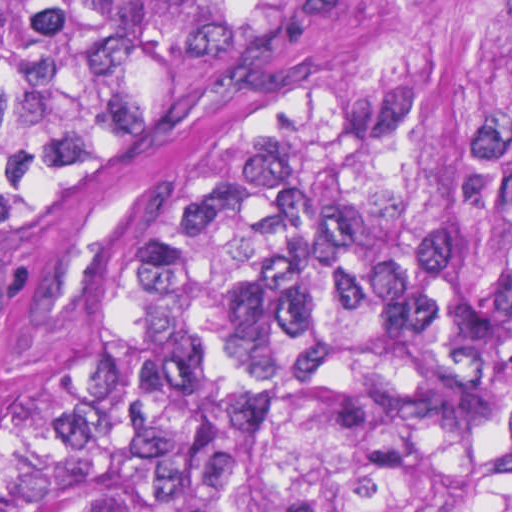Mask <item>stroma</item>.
I'll return each mask as SVG.
<instances>
[{
	"label": "stroma",
	"instance_id": "35a3bbf8",
	"mask_svg": "<svg viewBox=\"0 0 512 512\" xmlns=\"http://www.w3.org/2000/svg\"><path fill=\"white\" fill-rule=\"evenodd\" d=\"M27 311L20 289L0 314V423L8 386L29 359L23 343Z\"/></svg>",
	"mask_w": 512,
	"mask_h": 512
}]
</instances>
